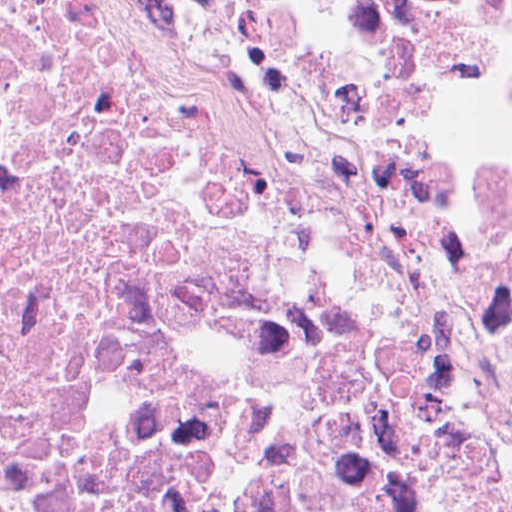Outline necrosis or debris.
<instances>
[{
    "instance_id": "1",
    "label": "necrosis or debris",
    "mask_w": 512,
    "mask_h": 512,
    "mask_svg": "<svg viewBox=\"0 0 512 512\" xmlns=\"http://www.w3.org/2000/svg\"><path fill=\"white\" fill-rule=\"evenodd\" d=\"M0 512H512V0H0Z\"/></svg>"
}]
</instances>
